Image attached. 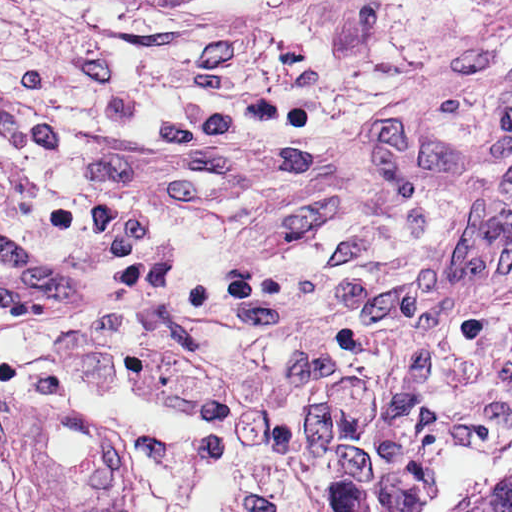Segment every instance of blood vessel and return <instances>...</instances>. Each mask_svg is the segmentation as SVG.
<instances>
[{"mask_svg":"<svg viewBox=\"0 0 512 512\" xmlns=\"http://www.w3.org/2000/svg\"><path fill=\"white\" fill-rule=\"evenodd\" d=\"M107 309L98 279L73 275L0 216V311L34 323H90Z\"/></svg>","mask_w":512,"mask_h":512,"instance_id":"obj_1","label":"blood vessel"}]
</instances>
